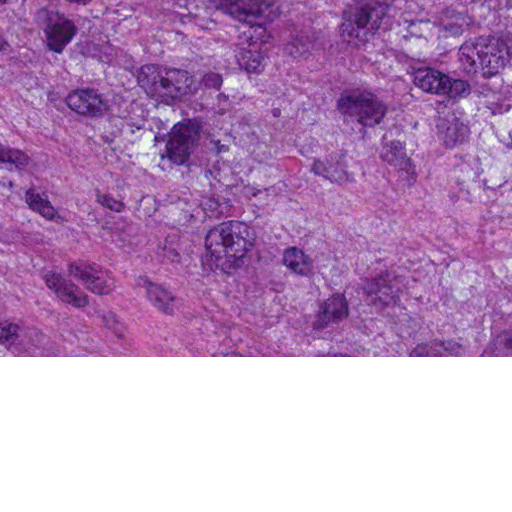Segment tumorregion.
Here are the masks:
<instances>
[{
    "instance_id": "e687c5a6",
    "label": "tumor region",
    "mask_w": 512,
    "mask_h": 512,
    "mask_svg": "<svg viewBox=\"0 0 512 512\" xmlns=\"http://www.w3.org/2000/svg\"><path fill=\"white\" fill-rule=\"evenodd\" d=\"M0 356H512V0H0Z\"/></svg>"
}]
</instances>
